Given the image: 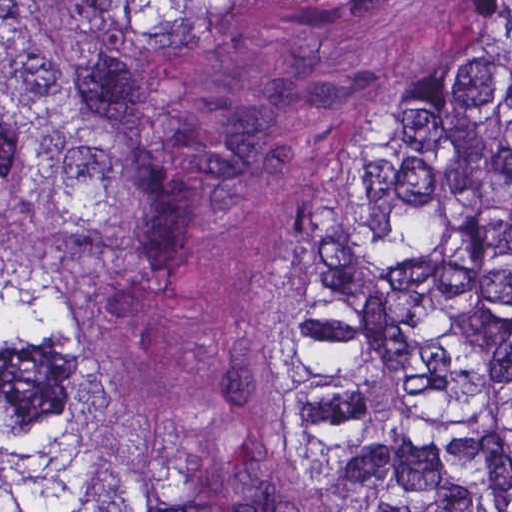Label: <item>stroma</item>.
<instances>
[{
    "mask_svg": "<svg viewBox=\"0 0 512 512\" xmlns=\"http://www.w3.org/2000/svg\"><path fill=\"white\" fill-rule=\"evenodd\" d=\"M295 1L133 34L196 220L185 294L77 376V437L141 512H359L300 422L294 312L336 200L482 1Z\"/></svg>",
    "mask_w": 512,
    "mask_h": 512,
    "instance_id": "obj_1",
    "label": "stroma"
}]
</instances>
